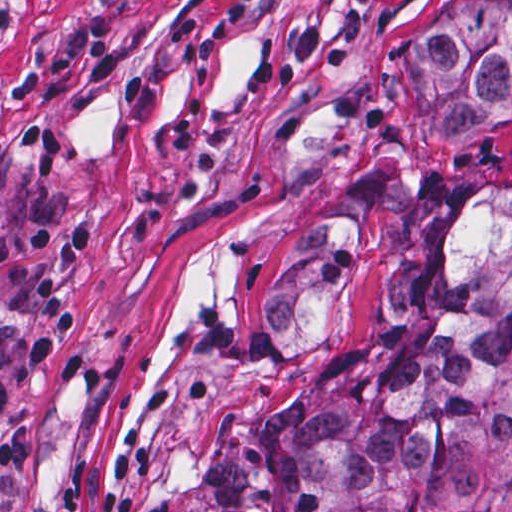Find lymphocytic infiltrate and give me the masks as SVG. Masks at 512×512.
Listing matches in <instances>:
<instances>
[{
  "label": "lymphocytic infiltrate",
  "instance_id": "1",
  "mask_svg": "<svg viewBox=\"0 0 512 512\" xmlns=\"http://www.w3.org/2000/svg\"><path fill=\"white\" fill-rule=\"evenodd\" d=\"M99 239L100 225L94 220L17 238L9 236L0 221V264L7 261L21 297L40 305L32 321H0V414L11 410L18 373L43 366L81 326L77 301L58 277L37 266L35 257H53L65 273L77 275L91 260Z\"/></svg>",
  "mask_w": 512,
  "mask_h": 512
}]
</instances>
